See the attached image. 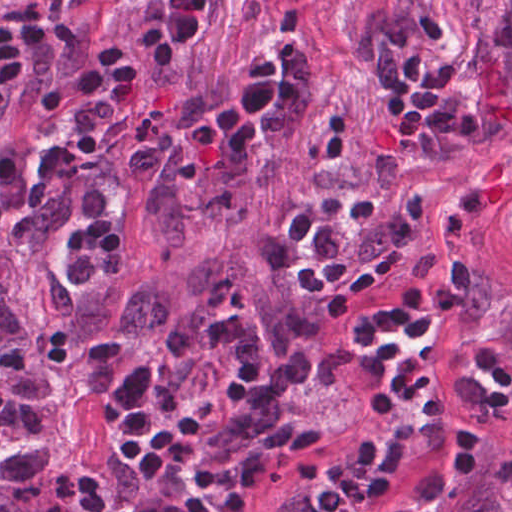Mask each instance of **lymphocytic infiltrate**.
<instances>
[{
    "instance_id": "lymphocytic-infiltrate-1",
    "label": "lymphocytic infiltrate",
    "mask_w": 512,
    "mask_h": 512,
    "mask_svg": "<svg viewBox=\"0 0 512 512\" xmlns=\"http://www.w3.org/2000/svg\"><path fill=\"white\" fill-rule=\"evenodd\" d=\"M476 288L473 260H456L449 277L420 275L345 357L360 367L362 404L373 420L433 421L437 385L409 351L424 352L434 329L468 306ZM405 467L406 452H388L378 479L329 483L317 493L312 512H372L395 491Z\"/></svg>"
}]
</instances>
